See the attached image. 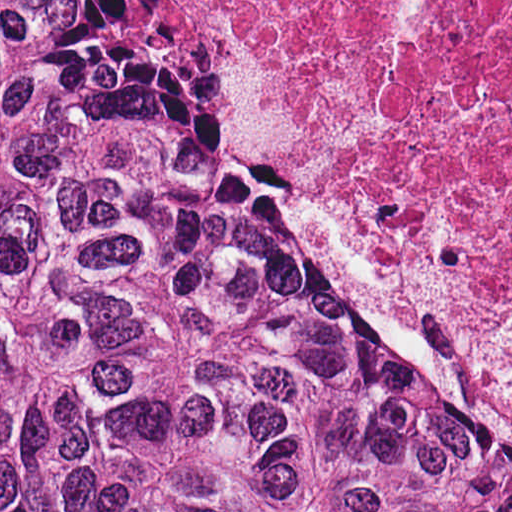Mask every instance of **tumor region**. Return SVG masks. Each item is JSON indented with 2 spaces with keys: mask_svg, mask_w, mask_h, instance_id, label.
Instances as JSON below:
<instances>
[{
  "mask_svg": "<svg viewBox=\"0 0 512 512\" xmlns=\"http://www.w3.org/2000/svg\"><path fill=\"white\" fill-rule=\"evenodd\" d=\"M0 512H512V405L126 0H0Z\"/></svg>",
  "mask_w": 512,
  "mask_h": 512,
  "instance_id": "tumor-region-1",
  "label": "tumor region"
}]
</instances>
